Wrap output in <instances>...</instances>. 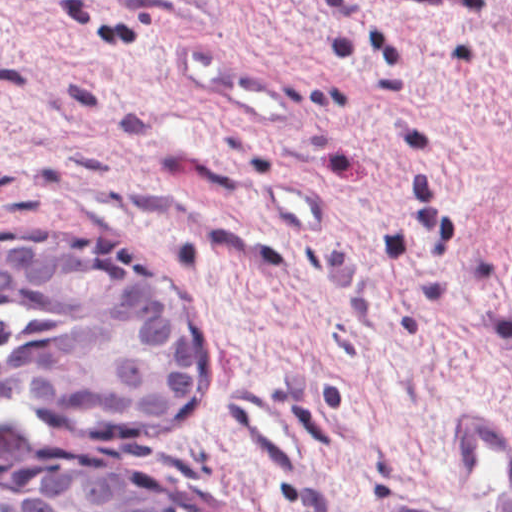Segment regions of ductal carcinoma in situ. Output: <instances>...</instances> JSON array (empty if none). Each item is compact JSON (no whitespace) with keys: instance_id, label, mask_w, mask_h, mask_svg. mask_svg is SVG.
<instances>
[{"instance_id":"obj_1","label":"ductal carcinoma in situ","mask_w":512,"mask_h":512,"mask_svg":"<svg viewBox=\"0 0 512 512\" xmlns=\"http://www.w3.org/2000/svg\"><path fill=\"white\" fill-rule=\"evenodd\" d=\"M0 420V512H200L75 423Z\"/></svg>"}]
</instances>
